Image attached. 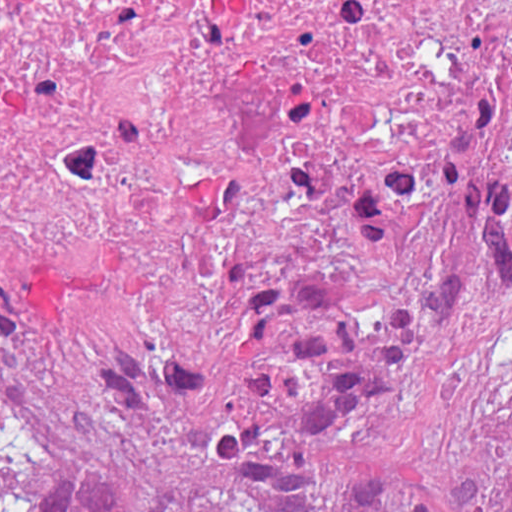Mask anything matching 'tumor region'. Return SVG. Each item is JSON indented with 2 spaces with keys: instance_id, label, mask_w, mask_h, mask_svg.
<instances>
[{
  "instance_id": "e687c5a6",
  "label": "tumor region",
  "mask_w": 512,
  "mask_h": 512,
  "mask_svg": "<svg viewBox=\"0 0 512 512\" xmlns=\"http://www.w3.org/2000/svg\"><path fill=\"white\" fill-rule=\"evenodd\" d=\"M0 512H512V122L220 196L0 120Z\"/></svg>"
}]
</instances>
